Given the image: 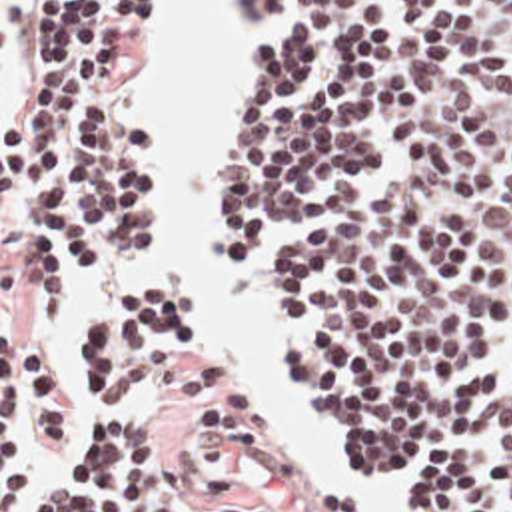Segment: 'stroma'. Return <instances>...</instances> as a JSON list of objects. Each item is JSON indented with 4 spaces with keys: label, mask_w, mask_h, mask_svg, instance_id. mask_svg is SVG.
<instances>
[{
    "label": "stroma",
    "mask_w": 512,
    "mask_h": 512,
    "mask_svg": "<svg viewBox=\"0 0 512 512\" xmlns=\"http://www.w3.org/2000/svg\"><path fill=\"white\" fill-rule=\"evenodd\" d=\"M168 12H170V0H160V26L152 35H142L140 73L128 87L118 89L116 97H114V113L120 119V123L130 125L136 131H140L150 145V175H152L154 187L158 191V205H160V245H158L156 253L146 263H142L138 267L106 273L74 305H70L56 319L34 321L26 315L22 291L18 287V213H16L14 195H12V179L2 173V125L8 123L16 115V111L20 107V99H22L24 0H0V512H2V341L10 339V337L32 341V343L44 347L58 361V365L62 367L64 375L68 377V381L74 389V425L78 429L84 419V413L88 409V403L80 389V367L72 353V333H74L76 319H78L80 309L86 303V299L92 293H96L100 287H104L106 283H110L118 277H126V275L162 277L172 287L180 289L184 295L190 297L188 289L184 287V283L178 279V275L166 261V157L152 141L146 125L132 111L128 95H126V91H130L146 81V77L154 65V41L162 29ZM290 12H292V8L288 4L284 18L268 31L234 33V31H228V0H224V4H222V12H220L216 28L232 41V45L240 57V67H238V81H236V87L232 91L230 105H228L218 173H216V185H214V197H212V269L222 287H226L242 297V301L254 315L262 335L278 347V351L288 367V373L296 385L303 429H280L274 423V441L270 443V447L266 451H262L258 455L230 453V451L222 449L206 433V429H192L180 437V441L174 445V451L192 459L196 481H200L204 485H216L218 475L232 473L234 479L238 481V485L246 493L258 495L268 505H272L282 512H303L282 491L280 463H282V451H284L290 435H313L327 449L335 469L343 477H347L369 501L393 512H435L429 503H425L421 497H417L413 493H403V495L369 493L363 487V483L349 471V467L331 453L323 433L317 429V425L313 423V419L309 417V413L305 409L296 363L274 325V297L266 287V269H268L272 255H288V253L301 251L305 247L317 245L319 243L317 231L274 239L272 243H268L260 261L256 265H252L232 251V247L226 239V233L222 229V185H224V177H226L228 153H230V143H232V135H234V127H236V119H238L240 99L244 95L246 83L250 79V73L254 69V63L258 59L260 51L270 41V37L286 24ZM12 173H14V169H12ZM14 179H16V173H14ZM202 355H210V353L198 345L196 331H192V335L184 343V347L176 355H172L168 361L162 363L158 379L154 381V385L150 387V391L140 401V405L134 413L136 425H148V423L156 421L166 411L178 371ZM246 395H250V393H246ZM18 425L22 429L26 447H28L32 459L36 461L38 469L46 471L50 467V461L34 447L20 417H18Z\"/></svg>",
    "instance_id": "35a3bbf8"
}]
</instances>
